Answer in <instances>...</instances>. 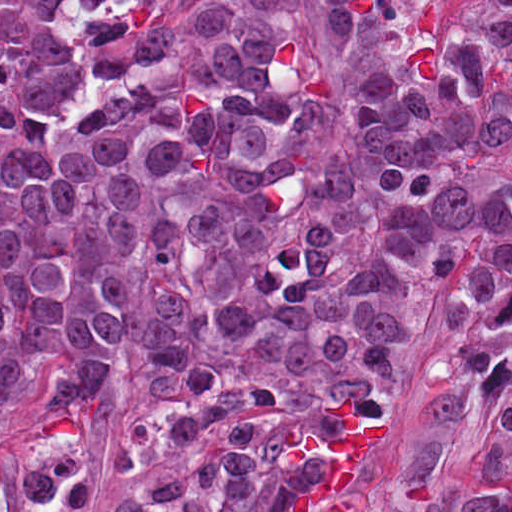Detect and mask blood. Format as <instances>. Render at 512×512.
<instances>
[{"label": "blood", "instance_id": "obj_1", "mask_svg": "<svg viewBox=\"0 0 512 512\" xmlns=\"http://www.w3.org/2000/svg\"><path fill=\"white\" fill-rule=\"evenodd\" d=\"M338 411L343 422L337 435H324L311 427L289 441L286 455L299 463L314 461L321 450L332 460L329 474L317 484L302 487L295 496L297 511L346 512V488L353 465L377 440L352 410L341 387L331 391L325 404Z\"/></svg>", "mask_w": 512, "mask_h": 512}]
</instances>
